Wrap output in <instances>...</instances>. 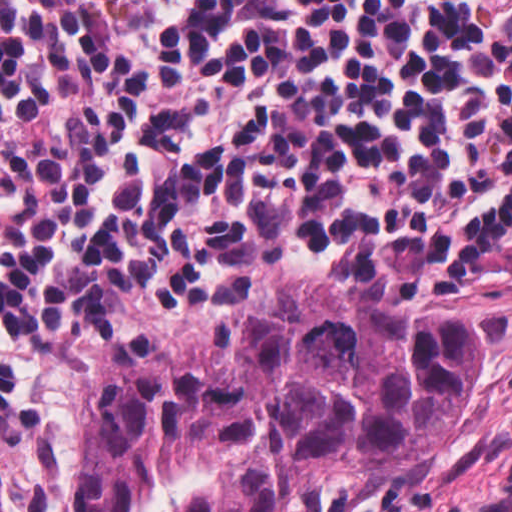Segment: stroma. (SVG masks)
<instances>
[{"mask_svg":"<svg viewBox=\"0 0 512 512\" xmlns=\"http://www.w3.org/2000/svg\"><path fill=\"white\" fill-rule=\"evenodd\" d=\"M277 291H344L371 307L435 303L477 315V357L467 407L442 449L403 479L294 495L280 512H409L512 452V263L471 287L378 283L341 267H241L221 276L187 312L147 323H99L67 401V468L59 511L79 512L88 425L103 365L178 346L227 340L248 300Z\"/></svg>","mask_w":512,"mask_h":512,"instance_id":"stroma-1","label":"stroma"}]
</instances>
